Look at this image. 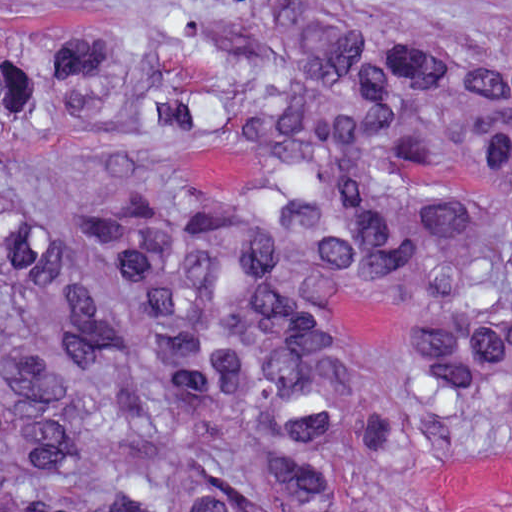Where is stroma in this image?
<instances>
[{"instance_id": "stroma-1", "label": "stroma", "mask_w": 512, "mask_h": 512, "mask_svg": "<svg viewBox=\"0 0 512 512\" xmlns=\"http://www.w3.org/2000/svg\"><path fill=\"white\" fill-rule=\"evenodd\" d=\"M60 0H0V11ZM416 512H512V431L447 451L417 482Z\"/></svg>"}]
</instances>
